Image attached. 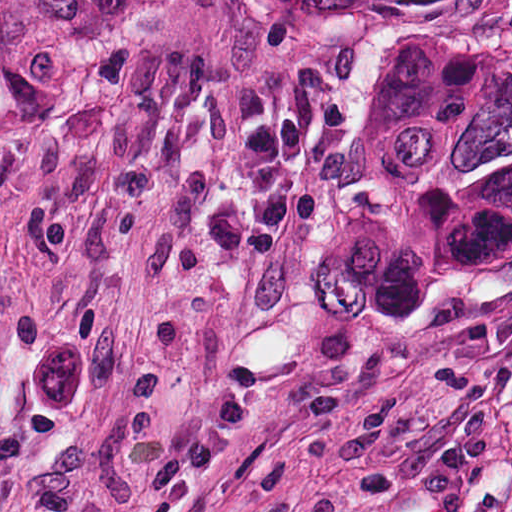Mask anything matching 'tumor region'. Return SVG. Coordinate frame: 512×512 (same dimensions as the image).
I'll return each mask as SVG.
<instances>
[{
  "label": "tumor region",
  "mask_w": 512,
  "mask_h": 512,
  "mask_svg": "<svg viewBox=\"0 0 512 512\" xmlns=\"http://www.w3.org/2000/svg\"><path fill=\"white\" fill-rule=\"evenodd\" d=\"M512 258V2H397L345 77L315 280L416 322Z\"/></svg>",
  "instance_id": "obj_1"
}]
</instances>
